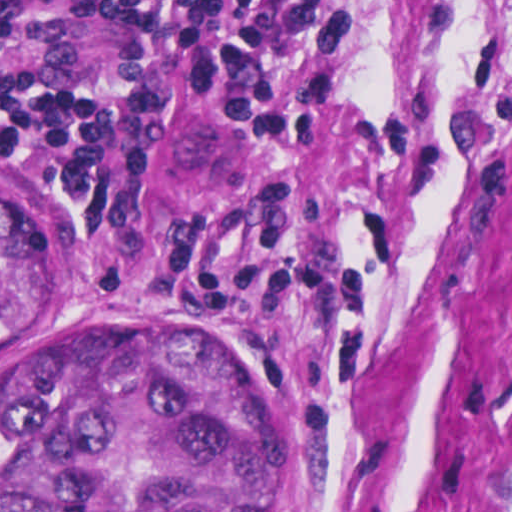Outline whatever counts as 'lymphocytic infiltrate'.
I'll return each mask as SVG.
<instances>
[{
	"label": "lymphocytic infiltrate",
	"instance_id": "lymphocytic-infiltrate-1",
	"mask_svg": "<svg viewBox=\"0 0 512 512\" xmlns=\"http://www.w3.org/2000/svg\"><path fill=\"white\" fill-rule=\"evenodd\" d=\"M288 4L0 0V145L60 192L105 263L285 332L306 328L329 290L294 219L158 220L133 190V170L157 112L210 83L274 144L300 142L321 104Z\"/></svg>",
	"mask_w": 512,
	"mask_h": 512
}]
</instances>
